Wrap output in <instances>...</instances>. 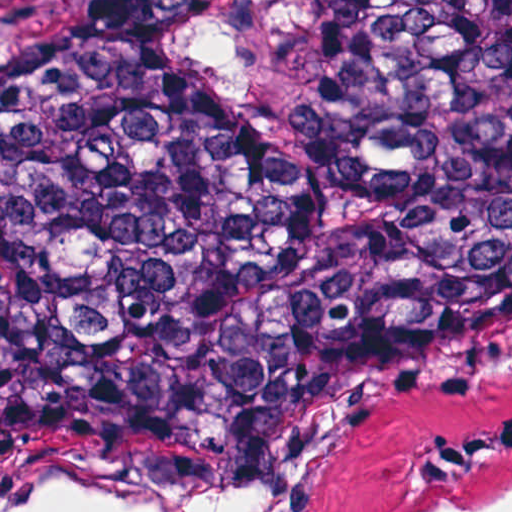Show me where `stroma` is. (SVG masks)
Returning a JSON list of instances; mask_svg holds the SVG:
<instances>
[{
    "label": "stroma",
    "instance_id": "35a3bbf8",
    "mask_svg": "<svg viewBox=\"0 0 512 512\" xmlns=\"http://www.w3.org/2000/svg\"><path fill=\"white\" fill-rule=\"evenodd\" d=\"M173 48L210 84L241 99L264 136L310 90L312 0H210L181 18ZM459 411L248 413L112 431H0V503L136 480H216L299 464L261 512H446L512 475V454L445 479L412 474Z\"/></svg>",
    "mask_w": 512,
    "mask_h": 512
}]
</instances>
